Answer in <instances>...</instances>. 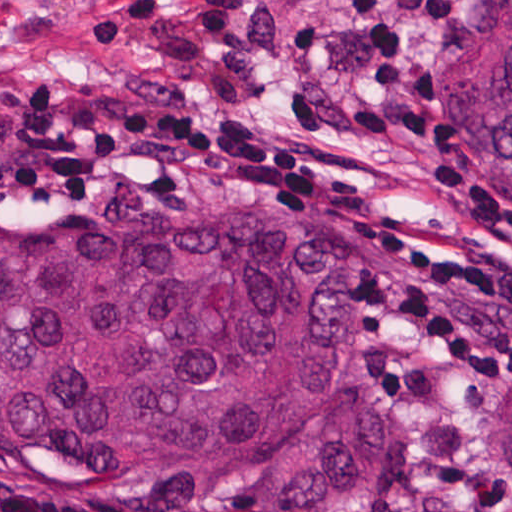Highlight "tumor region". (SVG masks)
I'll return each mask as SVG.
<instances>
[{"mask_svg":"<svg viewBox=\"0 0 512 512\" xmlns=\"http://www.w3.org/2000/svg\"><path fill=\"white\" fill-rule=\"evenodd\" d=\"M440 101L512 180V0H477ZM355 323L310 204L121 215L0 199V465L198 510L380 512L397 438L348 405ZM497 469L512 480V413Z\"/></svg>","mask_w":512,"mask_h":512,"instance_id":"1","label":"tumor region"}]
</instances>
